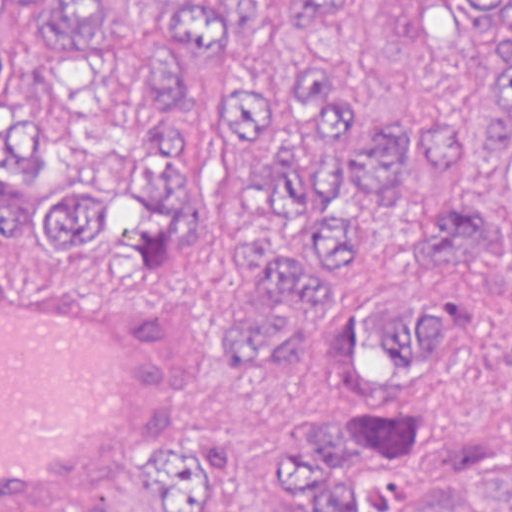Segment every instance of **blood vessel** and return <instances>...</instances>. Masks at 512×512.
Listing matches in <instances>:
<instances>
[{"mask_svg":"<svg viewBox=\"0 0 512 512\" xmlns=\"http://www.w3.org/2000/svg\"><path fill=\"white\" fill-rule=\"evenodd\" d=\"M0 268V512H67L190 430L215 318L184 283Z\"/></svg>","mask_w":512,"mask_h":512,"instance_id":"obj_1","label":"blood vessel"}]
</instances>
